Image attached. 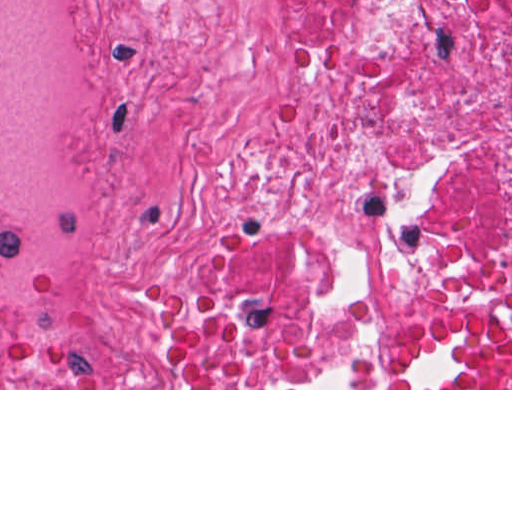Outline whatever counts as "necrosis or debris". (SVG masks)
Returning <instances> with one entry per match:
<instances>
[{
    "label": "necrosis or debris",
    "mask_w": 512,
    "mask_h": 512,
    "mask_svg": "<svg viewBox=\"0 0 512 512\" xmlns=\"http://www.w3.org/2000/svg\"><path fill=\"white\" fill-rule=\"evenodd\" d=\"M0 388H512V0H0Z\"/></svg>",
    "instance_id": "necrosis-or-debris-1"
}]
</instances>
